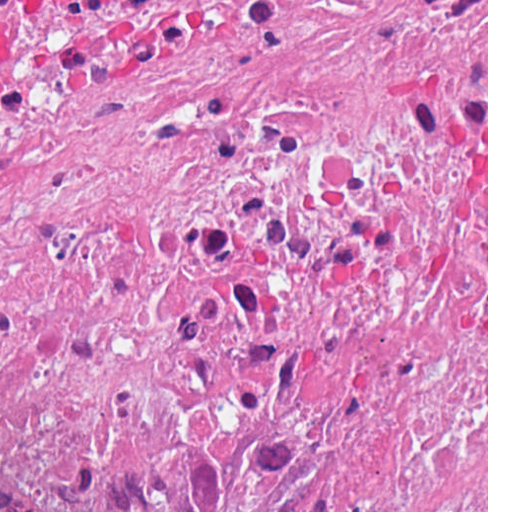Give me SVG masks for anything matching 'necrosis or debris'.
Returning a JSON list of instances; mask_svg holds the SVG:
<instances>
[{
  "label": "necrosis or debris",
  "mask_w": 512,
  "mask_h": 512,
  "mask_svg": "<svg viewBox=\"0 0 512 512\" xmlns=\"http://www.w3.org/2000/svg\"><path fill=\"white\" fill-rule=\"evenodd\" d=\"M436 411L438 0H0V512Z\"/></svg>",
  "instance_id": "4bbe7bcc"
}]
</instances>
